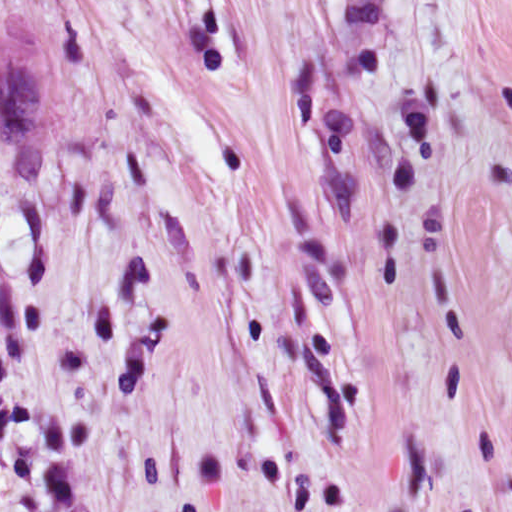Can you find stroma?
Here are the masks:
<instances>
[{
	"mask_svg": "<svg viewBox=\"0 0 512 512\" xmlns=\"http://www.w3.org/2000/svg\"><path fill=\"white\" fill-rule=\"evenodd\" d=\"M0 512H512V0H0Z\"/></svg>",
	"mask_w": 512,
	"mask_h": 512,
	"instance_id": "obj_1",
	"label": "stroma"
}]
</instances>
